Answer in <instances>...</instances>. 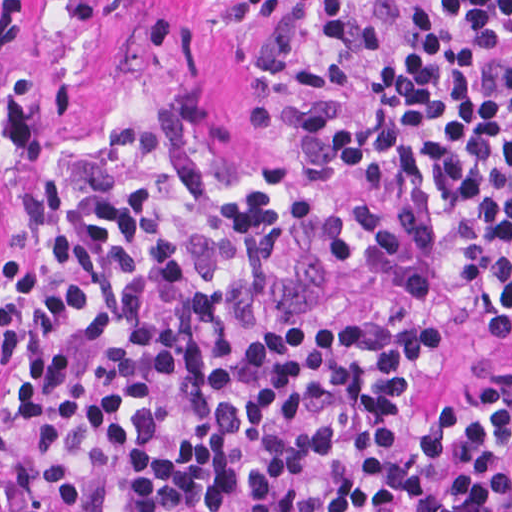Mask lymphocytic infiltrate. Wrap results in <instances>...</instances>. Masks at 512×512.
<instances>
[{
	"instance_id": "obj_1",
	"label": "lymphocytic infiltrate",
	"mask_w": 512,
	"mask_h": 512,
	"mask_svg": "<svg viewBox=\"0 0 512 512\" xmlns=\"http://www.w3.org/2000/svg\"><path fill=\"white\" fill-rule=\"evenodd\" d=\"M512 0H416L365 110L308 113L364 192L433 187L451 265L512 308ZM346 215L277 154L147 100L35 186L0 292V512H512V395L419 421L437 321L327 310Z\"/></svg>"
}]
</instances>
